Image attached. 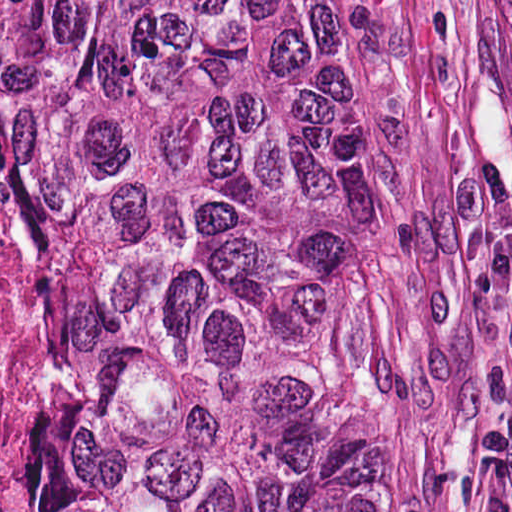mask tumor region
Instances as JSON below:
<instances>
[{
	"label": "tumor region",
	"mask_w": 512,
	"mask_h": 512,
	"mask_svg": "<svg viewBox=\"0 0 512 512\" xmlns=\"http://www.w3.org/2000/svg\"><path fill=\"white\" fill-rule=\"evenodd\" d=\"M0 232L46 406L13 512H389L343 0H0Z\"/></svg>",
	"instance_id": "1"
}]
</instances>
